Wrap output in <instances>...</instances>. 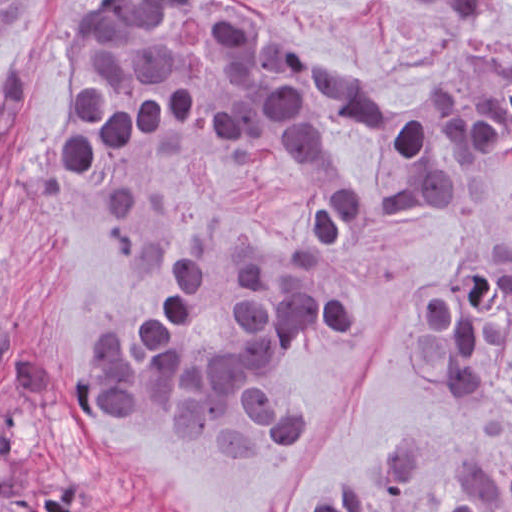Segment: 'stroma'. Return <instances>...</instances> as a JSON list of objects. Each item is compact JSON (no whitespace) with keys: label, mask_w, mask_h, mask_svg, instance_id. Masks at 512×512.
Listing matches in <instances>:
<instances>
[{"label":"stroma","mask_w":512,"mask_h":512,"mask_svg":"<svg viewBox=\"0 0 512 512\" xmlns=\"http://www.w3.org/2000/svg\"><path fill=\"white\" fill-rule=\"evenodd\" d=\"M107 0H37L0 36V304L56 364L38 435L103 512H301L332 491H387L397 463L425 465L431 512L458 495L464 464L512 460V404L498 383L472 399L425 381L408 357L418 304L478 243L460 218L377 215L335 240L309 237L341 199L382 176L339 132L318 164L237 162L154 137L94 174L48 162L68 125L83 19ZM319 44L344 73L406 98L422 77L478 46L489 76L512 66V0L464 11L414 0H257ZM311 255L354 308L340 339L295 346L277 371L286 402L313 411L306 437L270 449L168 440L119 422L78 426L63 404L67 354L91 360L119 331L162 324L175 250L195 255V339L235 337L230 245ZM3 379L0 376V393ZM0 512H33L0 494Z\"/></svg>","instance_id":"1"}]
</instances>
